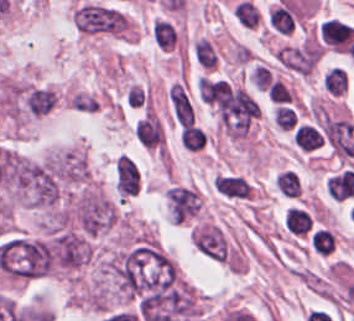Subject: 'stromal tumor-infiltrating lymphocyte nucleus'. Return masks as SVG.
Masks as SVG:
<instances>
[{
    "label": "stromal tumor-infiltrating lymphocyte nucleus",
    "mask_w": 354,
    "mask_h": 321,
    "mask_svg": "<svg viewBox=\"0 0 354 321\" xmlns=\"http://www.w3.org/2000/svg\"><path fill=\"white\" fill-rule=\"evenodd\" d=\"M215 188L226 198L249 199L253 187L247 177L235 172H221L215 177Z\"/></svg>",
    "instance_id": "bc302bb0"
},
{
    "label": "stromal tumor-infiltrating lymphocyte nucleus",
    "mask_w": 354,
    "mask_h": 321,
    "mask_svg": "<svg viewBox=\"0 0 354 321\" xmlns=\"http://www.w3.org/2000/svg\"><path fill=\"white\" fill-rule=\"evenodd\" d=\"M353 34L354 27L335 18H328L322 23L321 35L334 48H348Z\"/></svg>",
    "instance_id": "52c7bb5b"
},
{
    "label": "stromal tumor-infiltrating lymphocyte nucleus",
    "mask_w": 354,
    "mask_h": 321,
    "mask_svg": "<svg viewBox=\"0 0 354 321\" xmlns=\"http://www.w3.org/2000/svg\"><path fill=\"white\" fill-rule=\"evenodd\" d=\"M267 22L275 33L288 34L297 27V11L280 0L267 14Z\"/></svg>",
    "instance_id": "3290ff9b"
},
{
    "label": "stromal tumor-infiltrating lymphocyte nucleus",
    "mask_w": 354,
    "mask_h": 321,
    "mask_svg": "<svg viewBox=\"0 0 354 321\" xmlns=\"http://www.w3.org/2000/svg\"><path fill=\"white\" fill-rule=\"evenodd\" d=\"M285 225L295 236H308L313 230V216L307 207L291 204L285 214Z\"/></svg>",
    "instance_id": "abfb95fc"
},
{
    "label": "stromal tumor-infiltrating lymphocyte nucleus",
    "mask_w": 354,
    "mask_h": 321,
    "mask_svg": "<svg viewBox=\"0 0 354 321\" xmlns=\"http://www.w3.org/2000/svg\"><path fill=\"white\" fill-rule=\"evenodd\" d=\"M272 117L279 129L292 131L299 120L297 106L291 102L279 100L272 111Z\"/></svg>",
    "instance_id": "9ea309e8"
},
{
    "label": "stromal tumor-infiltrating lymphocyte nucleus",
    "mask_w": 354,
    "mask_h": 321,
    "mask_svg": "<svg viewBox=\"0 0 354 321\" xmlns=\"http://www.w3.org/2000/svg\"><path fill=\"white\" fill-rule=\"evenodd\" d=\"M179 137L188 151H201L209 140L204 126L198 123L184 126Z\"/></svg>",
    "instance_id": "f3e2335f"
},
{
    "label": "stromal tumor-infiltrating lymphocyte nucleus",
    "mask_w": 354,
    "mask_h": 321,
    "mask_svg": "<svg viewBox=\"0 0 354 321\" xmlns=\"http://www.w3.org/2000/svg\"><path fill=\"white\" fill-rule=\"evenodd\" d=\"M152 35L159 48L170 50L177 43L178 33L172 21L162 17L155 21Z\"/></svg>",
    "instance_id": "4f13568d"
},
{
    "label": "stromal tumor-infiltrating lymphocyte nucleus",
    "mask_w": 354,
    "mask_h": 321,
    "mask_svg": "<svg viewBox=\"0 0 354 321\" xmlns=\"http://www.w3.org/2000/svg\"><path fill=\"white\" fill-rule=\"evenodd\" d=\"M308 239L313 250L321 254H329L337 246V238L328 227H314Z\"/></svg>",
    "instance_id": "2a367800"
},
{
    "label": "stromal tumor-infiltrating lymphocyte nucleus",
    "mask_w": 354,
    "mask_h": 321,
    "mask_svg": "<svg viewBox=\"0 0 354 321\" xmlns=\"http://www.w3.org/2000/svg\"><path fill=\"white\" fill-rule=\"evenodd\" d=\"M275 182L282 196L298 197L301 192V178L291 169H283L276 176Z\"/></svg>",
    "instance_id": "4803ca6d"
},
{
    "label": "stromal tumor-infiltrating lymphocyte nucleus",
    "mask_w": 354,
    "mask_h": 321,
    "mask_svg": "<svg viewBox=\"0 0 354 321\" xmlns=\"http://www.w3.org/2000/svg\"><path fill=\"white\" fill-rule=\"evenodd\" d=\"M293 139L305 150H312L322 143L319 131L307 124L297 126Z\"/></svg>",
    "instance_id": "4245b91a"
},
{
    "label": "stromal tumor-infiltrating lymphocyte nucleus",
    "mask_w": 354,
    "mask_h": 321,
    "mask_svg": "<svg viewBox=\"0 0 354 321\" xmlns=\"http://www.w3.org/2000/svg\"><path fill=\"white\" fill-rule=\"evenodd\" d=\"M233 13L237 20L246 27H255L258 23V10L251 1L240 0L234 7Z\"/></svg>",
    "instance_id": "4c9ddf68"
}]
</instances>
